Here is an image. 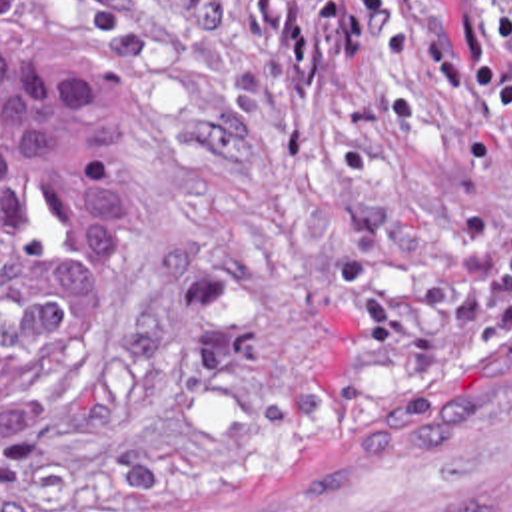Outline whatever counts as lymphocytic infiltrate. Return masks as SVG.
<instances>
[{
  "label": "lymphocytic infiltrate",
  "instance_id": "1",
  "mask_svg": "<svg viewBox=\"0 0 512 512\" xmlns=\"http://www.w3.org/2000/svg\"><path fill=\"white\" fill-rule=\"evenodd\" d=\"M423 74L451 80L467 100L512 126V18L449 0H338Z\"/></svg>",
  "mask_w": 512,
  "mask_h": 512
}]
</instances>
